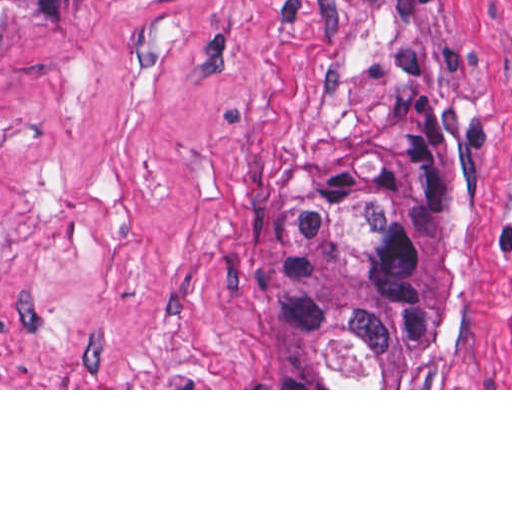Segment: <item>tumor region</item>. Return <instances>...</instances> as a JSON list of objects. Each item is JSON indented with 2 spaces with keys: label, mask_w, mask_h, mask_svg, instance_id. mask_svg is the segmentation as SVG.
<instances>
[{
  "label": "tumor region",
  "mask_w": 512,
  "mask_h": 512,
  "mask_svg": "<svg viewBox=\"0 0 512 512\" xmlns=\"http://www.w3.org/2000/svg\"><path fill=\"white\" fill-rule=\"evenodd\" d=\"M85 0H0V47ZM459 151V113L410 103L385 117L351 179L273 225L261 306L289 388H405L433 325L437 226Z\"/></svg>",
  "instance_id": "obj_1"
}]
</instances>
